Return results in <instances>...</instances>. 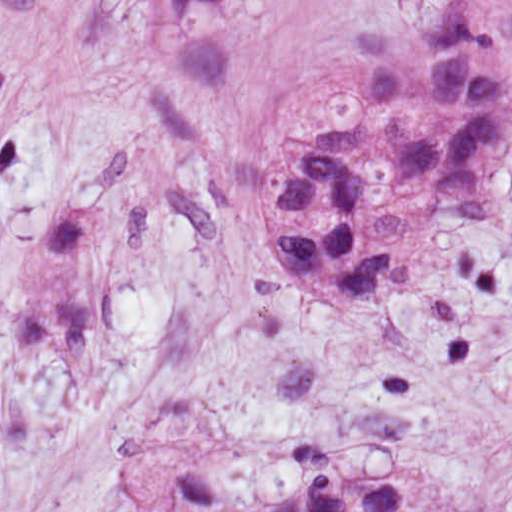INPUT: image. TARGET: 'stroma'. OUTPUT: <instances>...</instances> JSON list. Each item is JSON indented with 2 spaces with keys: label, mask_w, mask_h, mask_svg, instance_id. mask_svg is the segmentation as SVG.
<instances>
[{
  "label": "stroma",
  "mask_w": 512,
  "mask_h": 512,
  "mask_svg": "<svg viewBox=\"0 0 512 512\" xmlns=\"http://www.w3.org/2000/svg\"><path fill=\"white\" fill-rule=\"evenodd\" d=\"M456 0H0V512H264L392 460L356 512H512V0L482 220L361 308L279 290L294 139L355 42Z\"/></svg>",
  "instance_id": "obj_1"
}]
</instances>
